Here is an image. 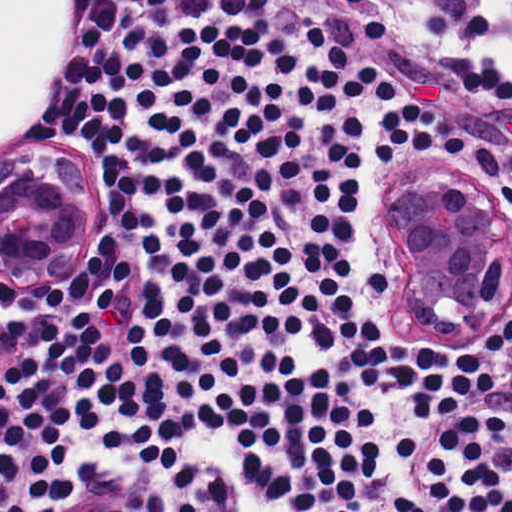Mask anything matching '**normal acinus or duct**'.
I'll return each mask as SVG.
<instances>
[{
    "instance_id": "normal-acinus-or-duct-1",
    "label": "normal acinus or duct",
    "mask_w": 512,
    "mask_h": 512,
    "mask_svg": "<svg viewBox=\"0 0 512 512\" xmlns=\"http://www.w3.org/2000/svg\"><path fill=\"white\" fill-rule=\"evenodd\" d=\"M380 222L398 256V315L423 341L512 317V201L447 153L382 190Z\"/></svg>"
}]
</instances>
